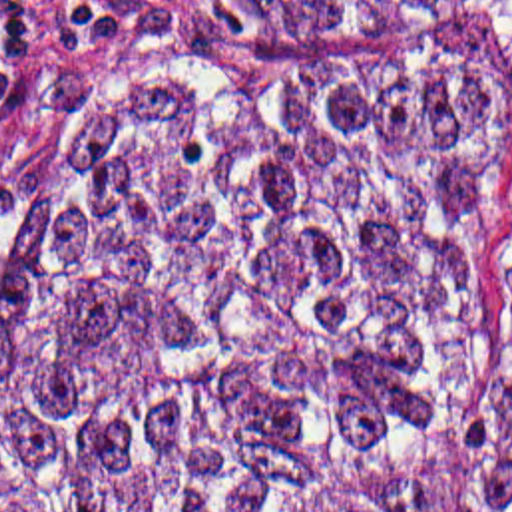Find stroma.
Masks as SVG:
<instances>
[{
  "mask_svg": "<svg viewBox=\"0 0 512 512\" xmlns=\"http://www.w3.org/2000/svg\"><path fill=\"white\" fill-rule=\"evenodd\" d=\"M193 56H466L484 77L504 129L502 249L424 476V512H446L472 482L490 364L512 332V0L411 44H253L209 0H0V249L66 125Z\"/></svg>",
  "mask_w": 512,
  "mask_h": 512,
  "instance_id": "obj_1",
  "label": "stroma"
}]
</instances>
